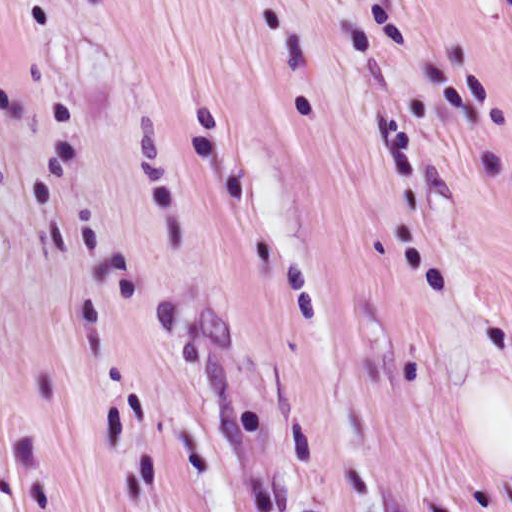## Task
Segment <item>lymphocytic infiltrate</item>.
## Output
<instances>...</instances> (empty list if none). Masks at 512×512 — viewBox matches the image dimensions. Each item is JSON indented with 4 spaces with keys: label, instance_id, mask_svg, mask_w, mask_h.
<instances>
[{
    "label": "lymphocytic infiltrate",
    "instance_id": "lymphocytic-infiltrate-1",
    "mask_svg": "<svg viewBox=\"0 0 512 512\" xmlns=\"http://www.w3.org/2000/svg\"><path fill=\"white\" fill-rule=\"evenodd\" d=\"M491 9L500 29L512 38V0H483Z\"/></svg>",
    "mask_w": 512,
    "mask_h": 512
}]
</instances>
